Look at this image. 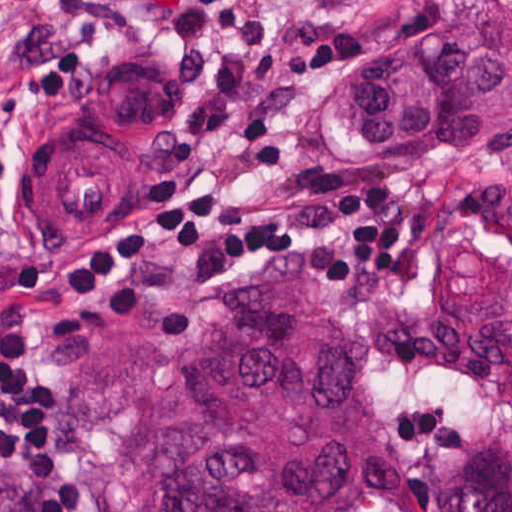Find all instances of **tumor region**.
<instances>
[{"mask_svg":"<svg viewBox=\"0 0 512 512\" xmlns=\"http://www.w3.org/2000/svg\"><path fill=\"white\" fill-rule=\"evenodd\" d=\"M357 154H512V0H433L422 30L349 80ZM59 440L88 482L150 512H363L375 430L352 334L289 277L259 282L189 341L85 332L55 363ZM0 512H38L0 483ZM433 512H512V423L458 441Z\"/></svg>","mask_w":512,"mask_h":512,"instance_id":"obj_1","label":"tumor region"}]
</instances>
